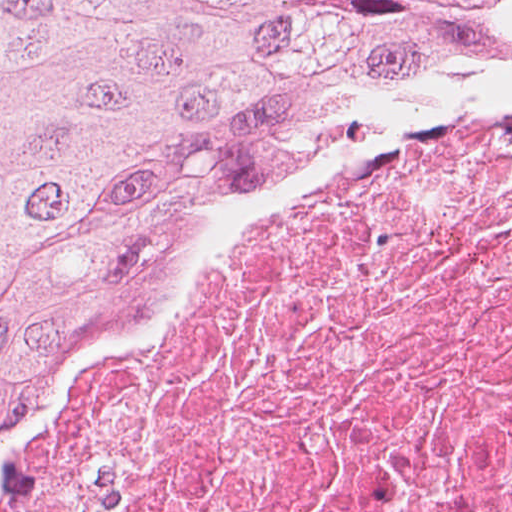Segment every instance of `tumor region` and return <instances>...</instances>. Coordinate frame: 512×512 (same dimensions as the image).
<instances>
[{
  "mask_svg": "<svg viewBox=\"0 0 512 512\" xmlns=\"http://www.w3.org/2000/svg\"><path fill=\"white\" fill-rule=\"evenodd\" d=\"M433 49L512 53V0H0V391L287 113Z\"/></svg>",
  "mask_w": 512,
  "mask_h": 512,
  "instance_id": "tumor-region-1",
  "label": "tumor region"
}]
</instances>
